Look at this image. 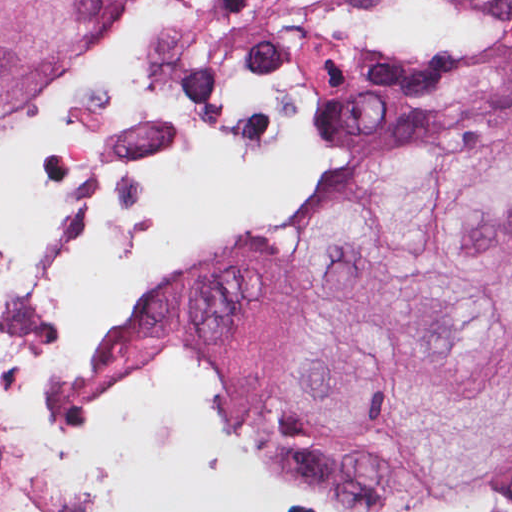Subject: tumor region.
<instances>
[{
    "label": "tumor region",
    "mask_w": 512,
    "mask_h": 512,
    "mask_svg": "<svg viewBox=\"0 0 512 512\" xmlns=\"http://www.w3.org/2000/svg\"><path fill=\"white\" fill-rule=\"evenodd\" d=\"M116 0H0V121ZM512 104V35L465 70ZM309 88L318 157L288 218L216 246L110 321L107 373L180 346L251 420V456L349 507L420 496L512 447V112L447 109L417 69Z\"/></svg>",
    "instance_id": "obj_1"
}]
</instances>
